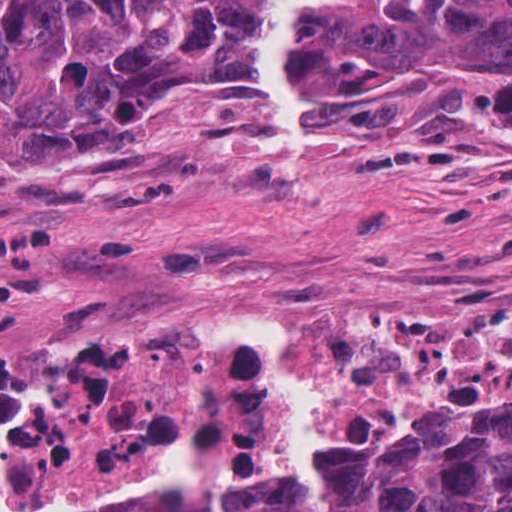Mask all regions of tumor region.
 <instances>
[{"mask_svg": "<svg viewBox=\"0 0 512 512\" xmlns=\"http://www.w3.org/2000/svg\"><path fill=\"white\" fill-rule=\"evenodd\" d=\"M258 0H0V145L124 164L169 119L255 97ZM313 97L389 98L457 76L512 110V0H323ZM219 512H307L293 460L225 484ZM318 512H512V384L323 453Z\"/></svg>", "mask_w": 512, "mask_h": 512, "instance_id": "e687c5a6", "label": "tumor region"}]
</instances>
